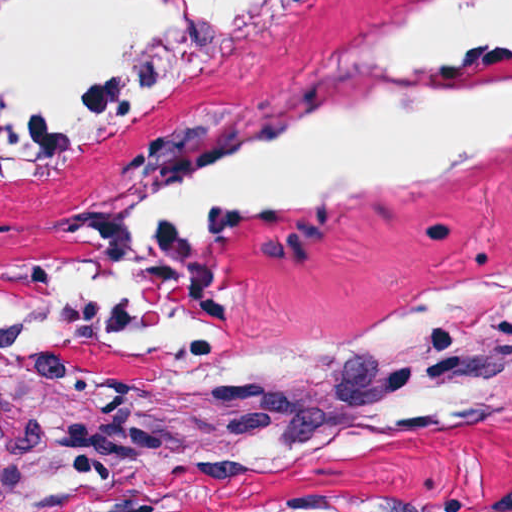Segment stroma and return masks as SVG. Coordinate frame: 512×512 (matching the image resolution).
I'll return each mask as SVG.
<instances>
[{
	"instance_id": "1",
	"label": "stroma",
	"mask_w": 512,
	"mask_h": 512,
	"mask_svg": "<svg viewBox=\"0 0 512 512\" xmlns=\"http://www.w3.org/2000/svg\"><path fill=\"white\" fill-rule=\"evenodd\" d=\"M438 1L259 0L68 166L0 180V280L217 146L294 118L358 47ZM480 68L512 83V42ZM511 249L512 140L426 184L231 229L210 272L215 350L157 363L31 338L0 351V512H512V342L438 371L350 438L125 454L138 413L246 340Z\"/></svg>"
}]
</instances>
